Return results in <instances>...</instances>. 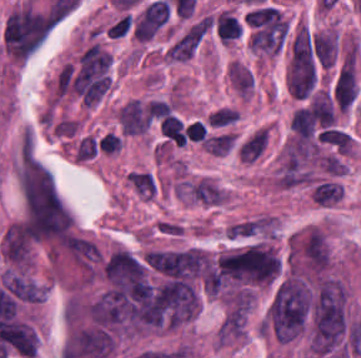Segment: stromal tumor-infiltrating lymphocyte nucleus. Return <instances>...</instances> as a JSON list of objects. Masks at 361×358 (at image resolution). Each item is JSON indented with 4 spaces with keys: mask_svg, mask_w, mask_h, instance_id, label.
I'll use <instances>...</instances> for the list:
<instances>
[{
    "mask_svg": "<svg viewBox=\"0 0 361 358\" xmlns=\"http://www.w3.org/2000/svg\"><path fill=\"white\" fill-rule=\"evenodd\" d=\"M219 40L230 42L239 38L240 25L238 21L228 13H221L216 19Z\"/></svg>",
    "mask_w": 361,
    "mask_h": 358,
    "instance_id": "bc302bb0",
    "label": "stromal tumor-infiltrating lymphocyte nucleus"
},
{
    "mask_svg": "<svg viewBox=\"0 0 361 358\" xmlns=\"http://www.w3.org/2000/svg\"><path fill=\"white\" fill-rule=\"evenodd\" d=\"M184 132L189 139L203 141L207 136V126L195 120L188 123Z\"/></svg>",
    "mask_w": 361,
    "mask_h": 358,
    "instance_id": "52c7bb5b",
    "label": "stromal tumor-infiltrating lymphocyte nucleus"
},
{
    "mask_svg": "<svg viewBox=\"0 0 361 358\" xmlns=\"http://www.w3.org/2000/svg\"><path fill=\"white\" fill-rule=\"evenodd\" d=\"M211 275H212V269H211V271H210V273L208 275V286H209V288H210V283H211Z\"/></svg>",
    "mask_w": 361,
    "mask_h": 358,
    "instance_id": "3290ff9b",
    "label": "stromal tumor-infiltrating lymphocyte nucleus"
}]
</instances>
